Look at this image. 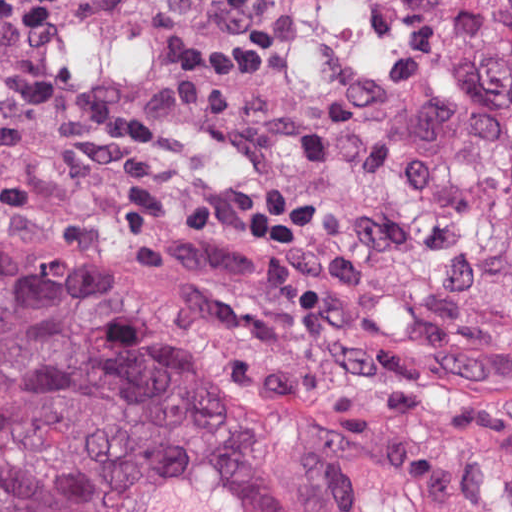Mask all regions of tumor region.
Masks as SVG:
<instances>
[{
	"label": "tumor region",
	"instance_id": "1",
	"mask_svg": "<svg viewBox=\"0 0 512 512\" xmlns=\"http://www.w3.org/2000/svg\"><path fill=\"white\" fill-rule=\"evenodd\" d=\"M256 174L386 267L512 291V0H227ZM0 512H483L0 267Z\"/></svg>",
	"mask_w": 512,
	"mask_h": 512
}]
</instances>
